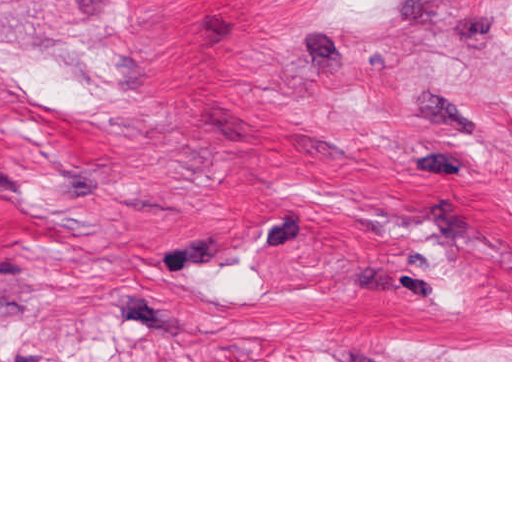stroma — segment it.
<instances>
[{
  "instance_id": "1",
  "label": "stroma",
  "mask_w": 512,
  "mask_h": 512,
  "mask_svg": "<svg viewBox=\"0 0 512 512\" xmlns=\"http://www.w3.org/2000/svg\"><path fill=\"white\" fill-rule=\"evenodd\" d=\"M0 362H512V0H0Z\"/></svg>"
}]
</instances>
